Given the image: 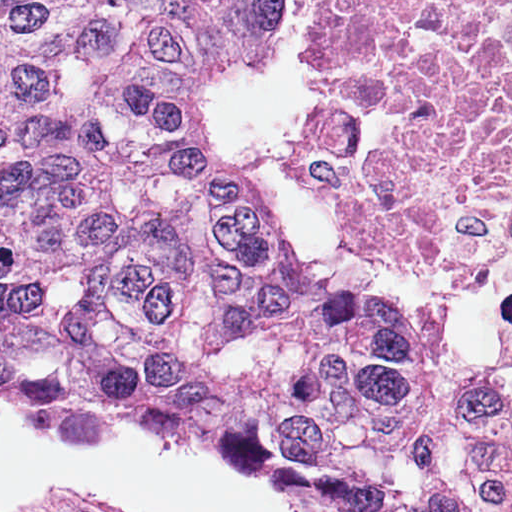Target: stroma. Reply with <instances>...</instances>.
Here are the masks:
<instances>
[{"mask_svg": "<svg viewBox=\"0 0 512 512\" xmlns=\"http://www.w3.org/2000/svg\"><path fill=\"white\" fill-rule=\"evenodd\" d=\"M479 284L489 297L497 334V358L487 365L495 371H512V288Z\"/></svg>", "mask_w": 512, "mask_h": 512, "instance_id": "stroma-1", "label": "stroma"}]
</instances>
